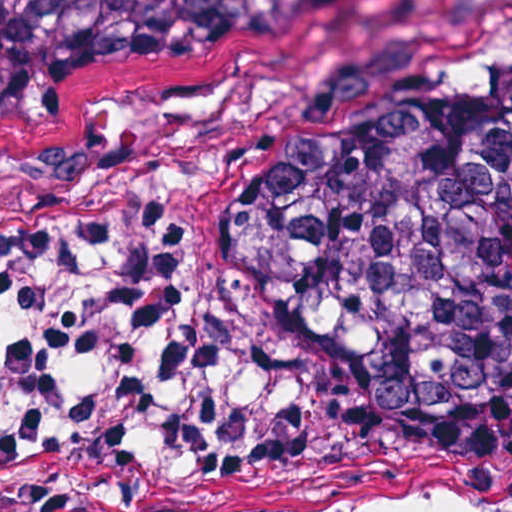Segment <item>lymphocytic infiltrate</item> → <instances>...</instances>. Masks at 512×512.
I'll return each instance as SVG.
<instances>
[{
  "mask_svg": "<svg viewBox=\"0 0 512 512\" xmlns=\"http://www.w3.org/2000/svg\"><path fill=\"white\" fill-rule=\"evenodd\" d=\"M184 228L152 196L0 236V512H143L276 462L291 435L232 416L231 379L287 352L217 337L184 288Z\"/></svg>",
  "mask_w": 512,
  "mask_h": 512,
  "instance_id": "obj_1",
  "label": "lymphocytic infiltrate"
}]
</instances>
